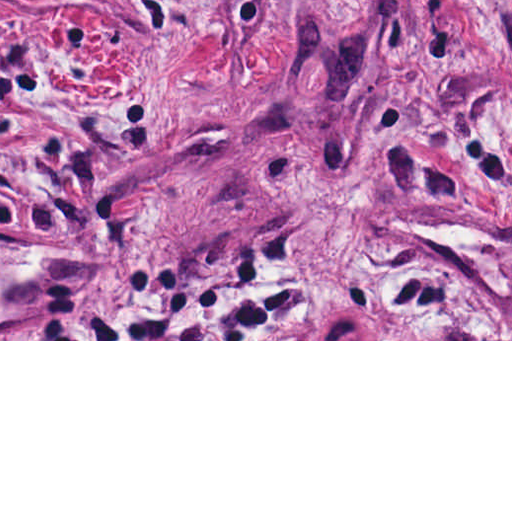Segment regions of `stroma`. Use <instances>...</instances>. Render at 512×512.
<instances>
[{
  "label": "stroma",
  "mask_w": 512,
  "mask_h": 512,
  "mask_svg": "<svg viewBox=\"0 0 512 512\" xmlns=\"http://www.w3.org/2000/svg\"><path fill=\"white\" fill-rule=\"evenodd\" d=\"M191 284L294 339H73ZM0 341H512V0H0Z\"/></svg>",
  "instance_id": "obj_1"
}]
</instances>
